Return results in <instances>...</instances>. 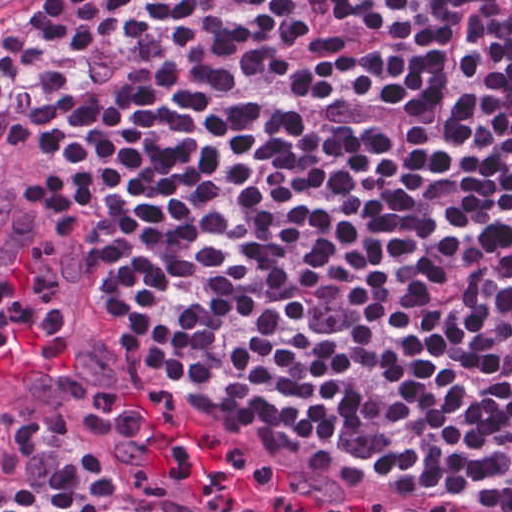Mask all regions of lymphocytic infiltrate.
I'll return each instance as SVG.
<instances>
[{
	"instance_id": "obj_1",
	"label": "lymphocytic infiltrate",
	"mask_w": 512,
	"mask_h": 512,
	"mask_svg": "<svg viewBox=\"0 0 512 512\" xmlns=\"http://www.w3.org/2000/svg\"><path fill=\"white\" fill-rule=\"evenodd\" d=\"M419 0H47L0 69V174L127 325ZM38 424L0 397V465Z\"/></svg>"
}]
</instances>
